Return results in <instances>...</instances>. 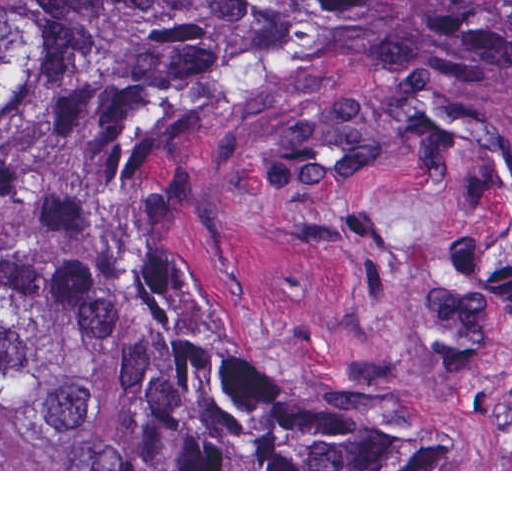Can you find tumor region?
I'll list each match as a JSON object with an SVG mask.
<instances>
[{"instance_id": "1", "label": "tumor region", "mask_w": 512, "mask_h": 512, "mask_svg": "<svg viewBox=\"0 0 512 512\" xmlns=\"http://www.w3.org/2000/svg\"><path fill=\"white\" fill-rule=\"evenodd\" d=\"M377 111L512 197V0H0V469H409L399 418L253 339L193 274L188 168L259 102ZM66 242V250L58 246ZM465 332L512 325V231L460 254Z\"/></svg>"}]
</instances>
